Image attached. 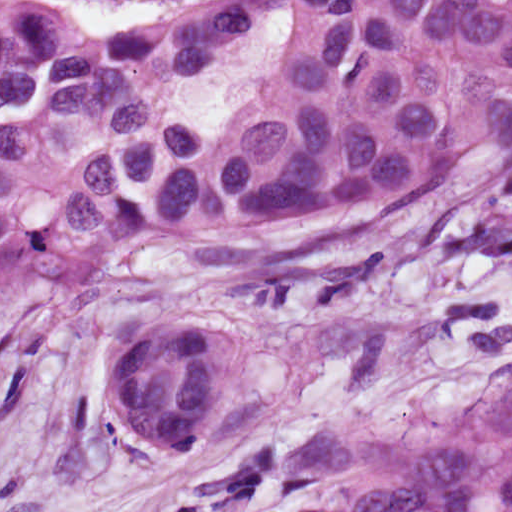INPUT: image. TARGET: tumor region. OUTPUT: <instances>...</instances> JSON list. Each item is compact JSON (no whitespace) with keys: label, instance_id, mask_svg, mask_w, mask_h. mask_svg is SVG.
Wrapping results in <instances>:
<instances>
[{"label":"tumor region","instance_id":"e687c5a6","mask_svg":"<svg viewBox=\"0 0 512 512\" xmlns=\"http://www.w3.org/2000/svg\"><path fill=\"white\" fill-rule=\"evenodd\" d=\"M511 150L510 0H147L109 24L0 0V282L17 293L160 236L246 276L256 306L367 280L384 265L364 212ZM108 400L143 452L191 451L224 401L217 328L134 324Z\"/></svg>","mask_w":512,"mask_h":512}]
</instances>
